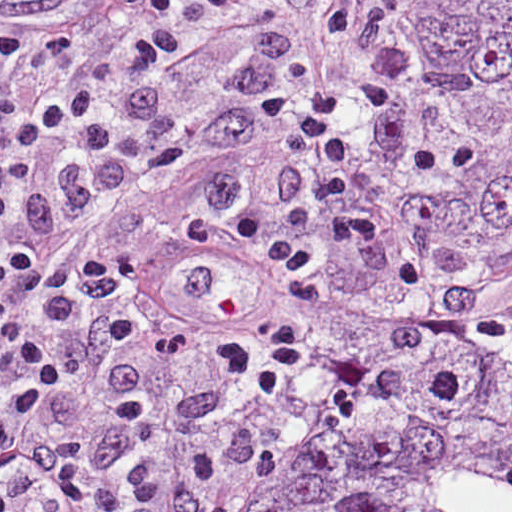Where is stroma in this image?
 <instances>
[{
  "instance_id": "stroma-1",
  "label": "stroma",
  "mask_w": 512,
  "mask_h": 512,
  "mask_svg": "<svg viewBox=\"0 0 512 512\" xmlns=\"http://www.w3.org/2000/svg\"><path fill=\"white\" fill-rule=\"evenodd\" d=\"M201 31L149 27L141 0H0V270L73 127Z\"/></svg>"
}]
</instances>
